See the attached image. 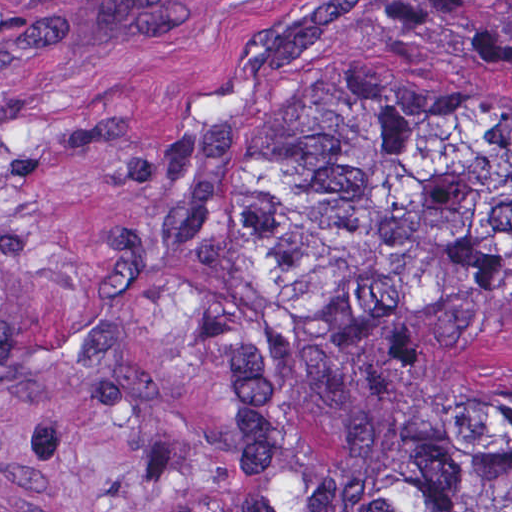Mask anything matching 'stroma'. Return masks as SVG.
<instances>
[{
  "mask_svg": "<svg viewBox=\"0 0 512 512\" xmlns=\"http://www.w3.org/2000/svg\"><path fill=\"white\" fill-rule=\"evenodd\" d=\"M512 0H0V512H205L280 134Z\"/></svg>",
  "mask_w": 512,
  "mask_h": 512,
  "instance_id": "obj_1",
  "label": "stroma"
}]
</instances>
